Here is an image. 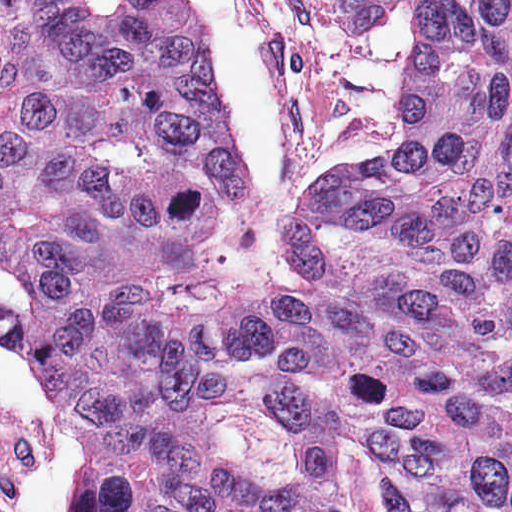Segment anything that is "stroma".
<instances>
[{"label": "stroma", "instance_id": "1", "mask_svg": "<svg viewBox=\"0 0 512 512\" xmlns=\"http://www.w3.org/2000/svg\"><path fill=\"white\" fill-rule=\"evenodd\" d=\"M195 1L220 117L261 224L280 226L307 173H351L401 138L426 48L419 8L350 26L332 0ZM0 292L33 295L1 262ZM0 512H83L69 410L37 359L1 340Z\"/></svg>", "mask_w": 512, "mask_h": 512}]
</instances>
